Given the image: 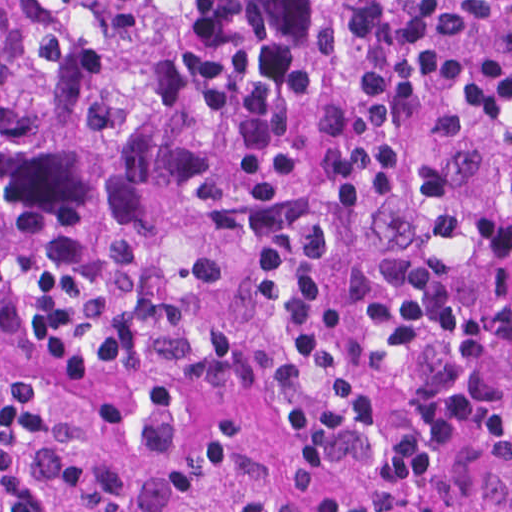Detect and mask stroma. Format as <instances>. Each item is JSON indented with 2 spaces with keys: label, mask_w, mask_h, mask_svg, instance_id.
<instances>
[{
  "label": "stroma",
  "mask_w": 512,
  "mask_h": 512,
  "mask_svg": "<svg viewBox=\"0 0 512 512\" xmlns=\"http://www.w3.org/2000/svg\"><path fill=\"white\" fill-rule=\"evenodd\" d=\"M262 483L273 512H313L287 454L268 448ZM418 512H512V466L489 458L458 463Z\"/></svg>",
  "instance_id": "obj_1"
}]
</instances>
